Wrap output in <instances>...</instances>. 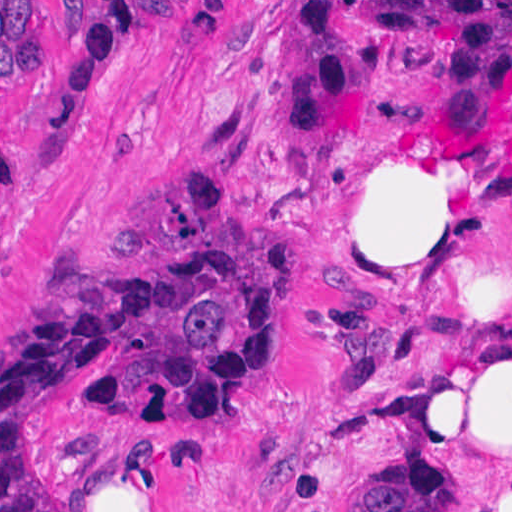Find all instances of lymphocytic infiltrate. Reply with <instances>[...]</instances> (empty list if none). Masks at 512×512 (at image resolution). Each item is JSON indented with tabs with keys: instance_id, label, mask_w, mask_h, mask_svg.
I'll use <instances>...</instances> for the list:
<instances>
[{
	"instance_id": "obj_1",
	"label": "lymphocytic infiltrate",
	"mask_w": 512,
	"mask_h": 512,
	"mask_svg": "<svg viewBox=\"0 0 512 512\" xmlns=\"http://www.w3.org/2000/svg\"><path fill=\"white\" fill-rule=\"evenodd\" d=\"M58 4V1H56ZM36 1H0V75L39 70ZM192 1H101L89 39L53 96L46 121L62 129L85 111L118 66V31L135 16ZM377 30L423 33L446 43L447 104L429 139L466 149L512 93V1H299L295 39L279 51L280 131L320 144L364 136L377 81ZM8 160L0 140V200Z\"/></svg>"
}]
</instances>
